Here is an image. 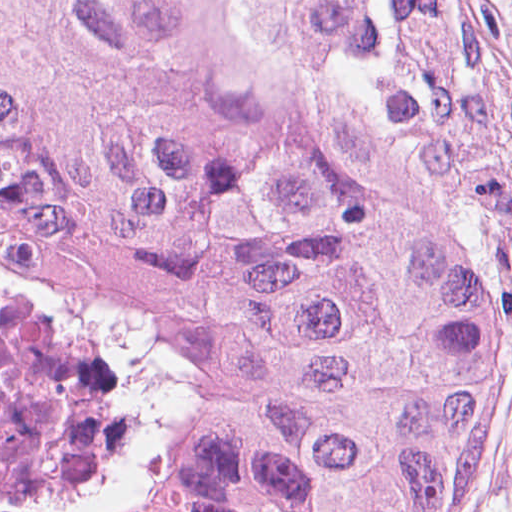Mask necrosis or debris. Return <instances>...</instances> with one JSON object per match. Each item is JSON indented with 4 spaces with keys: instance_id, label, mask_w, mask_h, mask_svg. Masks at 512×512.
<instances>
[{
    "instance_id": "4bbe7bcc",
    "label": "necrosis or debris",
    "mask_w": 512,
    "mask_h": 512,
    "mask_svg": "<svg viewBox=\"0 0 512 512\" xmlns=\"http://www.w3.org/2000/svg\"><path fill=\"white\" fill-rule=\"evenodd\" d=\"M0 512H186L131 357L2 243Z\"/></svg>"
}]
</instances>
